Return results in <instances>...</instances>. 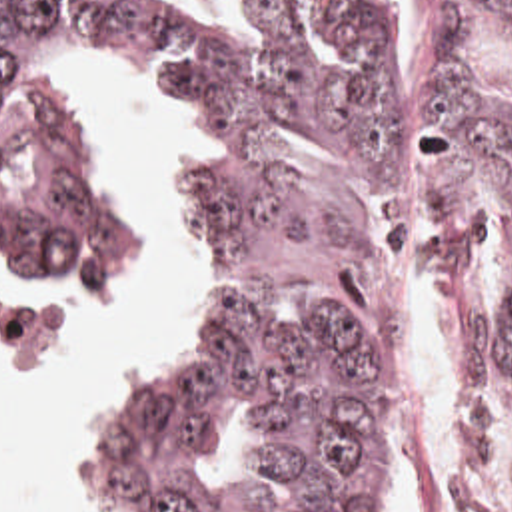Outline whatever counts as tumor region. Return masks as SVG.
<instances>
[{
  "label": "tumor region",
  "mask_w": 512,
  "mask_h": 512,
  "mask_svg": "<svg viewBox=\"0 0 512 512\" xmlns=\"http://www.w3.org/2000/svg\"><path fill=\"white\" fill-rule=\"evenodd\" d=\"M256 31H210L128 0H0V281H92L132 249V217L52 65L112 57L168 79L194 125L172 199L190 255L182 333L122 381L72 465V512H372L388 467L392 75L410 0H258ZM512 47V0H420L410 55V191L460 289L466 435L454 512L490 509L496 417L512 385V295L476 273L480 205L512 217V105L472 81ZM244 409L264 481L200 497L192 455Z\"/></svg>",
  "instance_id": "obj_1"
}]
</instances>
